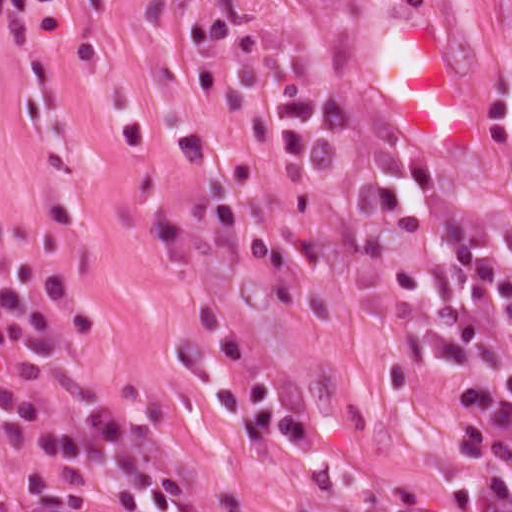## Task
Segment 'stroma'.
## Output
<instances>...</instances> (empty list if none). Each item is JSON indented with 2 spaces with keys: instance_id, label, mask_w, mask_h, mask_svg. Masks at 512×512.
Listing matches in <instances>:
<instances>
[{
  "instance_id": "35a3bbf8",
  "label": "stroma",
  "mask_w": 512,
  "mask_h": 512,
  "mask_svg": "<svg viewBox=\"0 0 512 512\" xmlns=\"http://www.w3.org/2000/svg\"><path fill=\"white\" fill-rule=\"evenodd\" d=\"M227 24L346 116L324 168H279L273 110L237 92L202 33ZM512 81V0H0V277L71 272L94 330L66 357L0 352V432L63 405L156 415L198 512H359L447 499V469L512 400L450 402L456 374L393 378L390 283L348 231L358 186L424 211L410 162L488 210L512 261V132L483 122ZM396 230L421 307H454L512 360L499 305L466 301L438 223Z\"/></svg>"
}]
</instances>
